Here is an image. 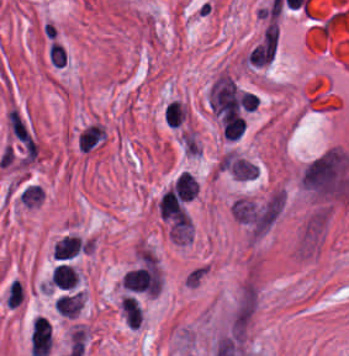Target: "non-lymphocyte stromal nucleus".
<instances>
[{
	"label": "non-lymphocyte stromal nucleus",
	"instance_id": "3746e769",
	"mask_svg": "<svg viewBox=\"0 0 349 356\" xmlns=\"http://www.w3.org/2000/svg\"><path fill=\"white\" fill-rule=\"evenodd\" d=\"M53 305L58 315L73 317L80 309L81 293L78 290L57 296Z\"/></svg>",
	"mask_w": 349,
	"mask_h": 356
},
{
	"label": "non-lymphocyte stromal nucleus",
	"instance_id": "81446118",
	"mask_svg": "<svg viewBox=\"0 0 349 356\" xmlns=\"http://www.w3.org/2000/svg\"><path fill=\"white\" fill-rule=\"evenodd\" d=\"M121 311L127 327L134 329L141 322V309L133 298H122Z\"/></svg>",
	"mask_w": 349,
	"mask_h": 356
},
{
	"label": "non-lymphocyte stromal nucleus",
	"instance_id": "a72fc3eb",
	"mask_svg": "<svg viewBox=\"0 0 349 356\" xmlns=\"http://www.w3.org/2000/svg\"><path fill=\"white\" fill-rule=\"evenodd\" d=\"M89 241L78 235H64L53 247V257L71 258L84 251Z\"/></svg>",
	"mask_w": 349,
	"mask_h": 356
},
{
	"label": "non-lymphocyte stromal nucleus",
	"instance_id": "fc2b8d12",
	"mask_svg": "<svg viewBox=\"0 0 349 356\" xmlns=\"http://www.w3.org/2000/svg\"><path fill=\"white\" fill-rule=\"evenodd\" d=\"M197 182L187 171H183L175 180L173 189L182 200H189L196 194Z\"/></svg>",
	"mask_w": 349,
	"mask_h": 356
},
{
	"label": "non-lymphocyte stromal nucleus",
	"instance_id": "7c5642bf",
	"mask_svg": "<svg viewBox=\"0 0 349 356\" xmlns=\"http://www.w3.org/2000/svg\"><path fill=\"white\" fill-rule=\"evenodd\" d=\"M207 273L206 263H199L196 266L186 270L184 277V286L194 288L199 284L202 278Z\"/></svg>",
	"mask_w": 349,
	"mask_h": 356
},
{
	"label": "non-lymphocyte stromal nucleus",
	"instance_id": "dd21d789",
	"mask_svg": "<svg viewBox=\"0 0 349 356\" xmlns=\"http://www.w3.org/2000/svg\"><path fill=\"white\" fill-rule=\"evenodd\" d=\"M106 141V131L101 121H88L78 131L77 149L91 153L100 148Z\"/></svg>",
	"mask_w": 349,
	"mask_h": 356
}]
</instances>
